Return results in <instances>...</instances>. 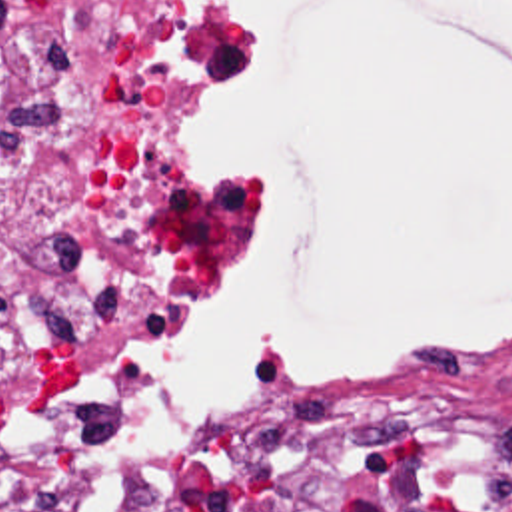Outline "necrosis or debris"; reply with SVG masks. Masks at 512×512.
<instances>
[{"instance_id": "1", "label": "necrosis or debris", "mask_w": 512, "mask_h": 512, "mask_svg": "<svg viewBox=\"0 0 512 512\" xmlns=\"http://www.w3.org/2000/svg\"><path fill=\"white\" fill-rule=\"evenodd\" d=\"M241 4L0 0V512H103L129 370L237 262ZM199 483L221 512H512V425L371 374L263 415Z\"/></svg>"}]
</instances>
